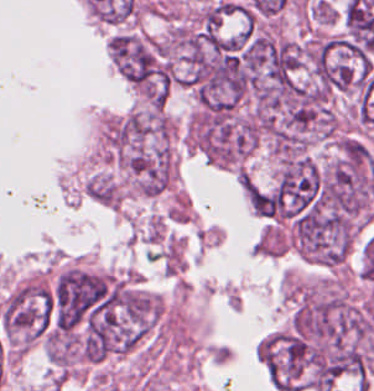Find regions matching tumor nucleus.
<instances>
[{
	"mask_svg": "<svg viewBox=\"0 0 374 391\" xmlns=\"http://www.w3.org/2000/svg\"><path fill=\"white\" fill-rule=\"evenodd\" d=\"M112 278L106 273L69 266L53 280L43 318L52 332L74 330Z\"/></svg>",
	"mask_w": 374,
	"mask_h": 391,
	"instance_id": "2f306a5c",
	"label": "tumor nucleus"
},
{
	"mask_svg": "<svg viewBox=\"0 0 374 391\" xmlns=\"http://www.w3.org/2000/svg\"><path fill=\"white\" fill-rule=\"evenodd\" d=\"M255 348L271 385L276 390L295 391L313 365L318 346L292 327L268 335Z\"/></svg>",
	"mask_w": 374,
	"mask_h": 391,
	"instance_id": "8643909e",
	"label": "tumor nucleus"
},
{
	"mask_svg": "<svg viewBox=\"0 0 374 391\" xmlns=\"http://www.w3.org/2000/svg\"><path fill=\"white\" fill-rule=\"evenodd\" d=\"M47 303L48 285L39 275L24 280L7 294L0 323L10 344L24 348L43 333Z\"/></svg>",
	"mask_w": 374,
	"mask_h": 391,
	"instance_id": "5ab6c2c4",
	"label": "tumor nucleus"
}]
</instances>
